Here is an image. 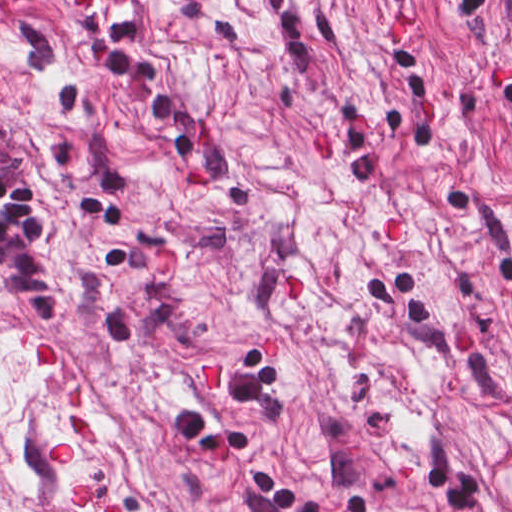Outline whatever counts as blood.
<instances>
[{
  "label": "blood",
  "mask_w": 512,
  "mask_h": 512,
  "mask_svg": "<svg viewBox=\"0 0 512 512\" xmlns=\"http://www.w3.org/2000/svg\"><path fill=\"white\" fill-rule=\"evenodd\" d=\"M280 296L285 300H301L304 290L301 278L295 269L285 270L278 277ZM269 349L277 357V332L270 334ZM35 356L44 362H60V359L50 341L40 339L35 346ZM225 375V360L208 361L199 367L198 386L200 392H213L220 386V379ZM66 451H54L49 458V467H64ZM99 499L105 507V512H125L122 505L105 502L96 497L91 488H80L73 493V502L83 506L90 498Z\"/></svg>",
  "instance_id": "blood-1"
}]
</instances>
